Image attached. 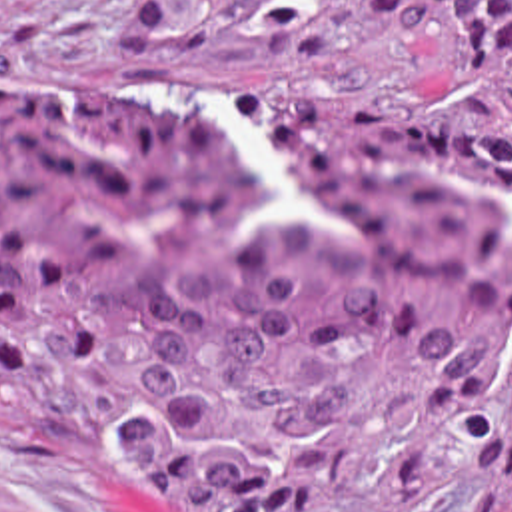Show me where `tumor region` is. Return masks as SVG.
<instances>
[{"label":"tumor region","instance_id":"1","mask_svg":"<svg viewBox=\"0 0 512 512\" xmlns=\"http://www.w3.org/2000/svg\"><path fill=\"white\" fill-rule=\"evenodd\" d=\"M448 117L0 79V439L142 512H512V0H280L422 37Z\"/></svg>","mask_w":512,"mask_h":512}]
</instances>
